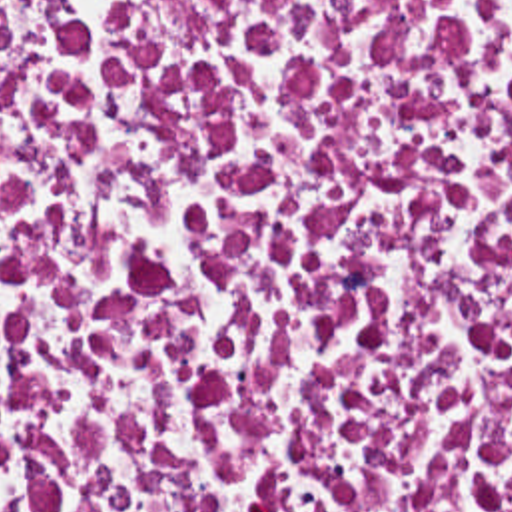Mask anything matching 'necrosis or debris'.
<instances>
[{"label": "necrosis or debris", "instance_id": "4bbe7bcc", "mask_svg": "<svg viewBox=\"0 0 512 512\" xmlns=\"http://www.w3.org/2000/svg\"><path fill=\"white\" fill-rule=\"evenodd\" d=\"M0 512H512V0H0Z\"/></svg>", "mask_w": 512, "mask_h": 512}]
</instances>
